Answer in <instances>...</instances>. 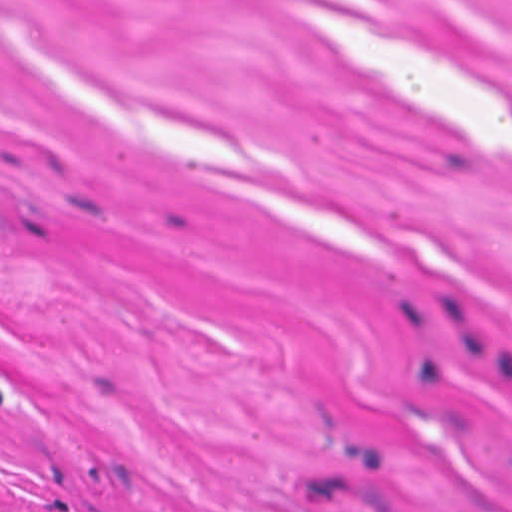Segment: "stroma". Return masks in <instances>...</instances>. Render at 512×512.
I'll return each mask as SVG.
<instances>
[{"mask_svg":"<svg viewBox=\"0 0 512 512\" xmlns=\"http://www.w3.org/2000/svg\"><path fill=\"white\" fill-rule=\"evenodd\" d=\"M0 512H512V0H0Z\"/></svg>","mask_w":512,"mask_h":512,"instance_id":"35a3bbf8","label":"stroma"}]
</instances>
